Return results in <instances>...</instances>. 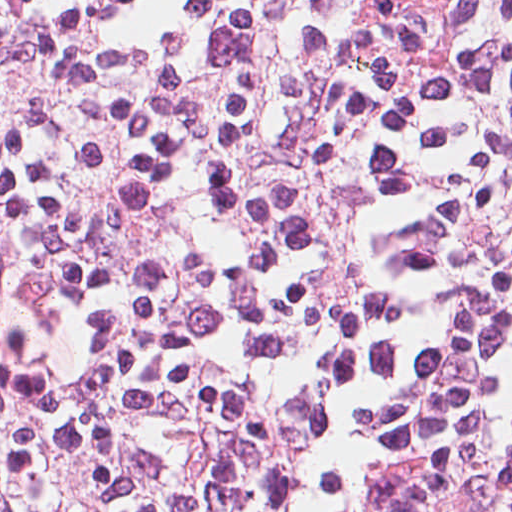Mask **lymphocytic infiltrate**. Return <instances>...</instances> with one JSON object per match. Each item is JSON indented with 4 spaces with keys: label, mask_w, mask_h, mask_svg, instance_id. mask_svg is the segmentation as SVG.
<instances>
[{
    "label": "lymphocytic infiltrate",
    "mask_w": 512,
    "mask_h": 512,
    "mask_svg": "<svg viewBox=\"0 0 512 512\" xmlns=\"http://www.w3.org/2000/svg\"><path fill=\"white\" fill-rule=\"evenodd\" d=\"M0 512H512V0H0Z\"/></svg>",
    "instance_id": "obj_1"
}]
</instances>
